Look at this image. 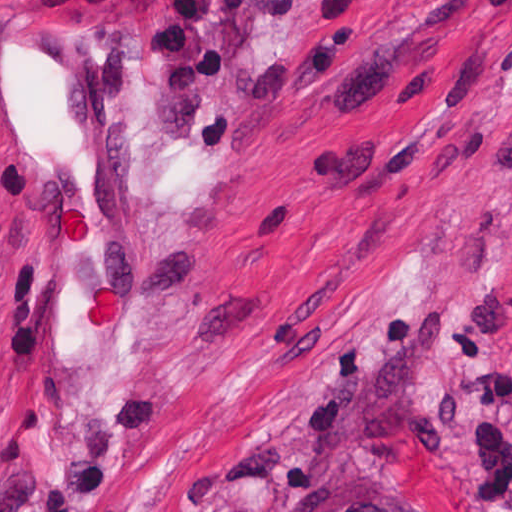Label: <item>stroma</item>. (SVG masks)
Wrapping results in <instances>:
<instances>
[{"instance_id":"stroma-1","label":"stroma","mask_w":512,"mask_h":512,"mask_svg":"<svg viewBox=\"0 0 512 512\" xmlns=\"http://www.w3.org/2000/svg\"><path fill=\"white\" fill-rule=\"evenodd\" d=\"M146 92L153 344L79 451L10 369L0 512H512V0H93Z\"/></svg>"}]
</instances>
